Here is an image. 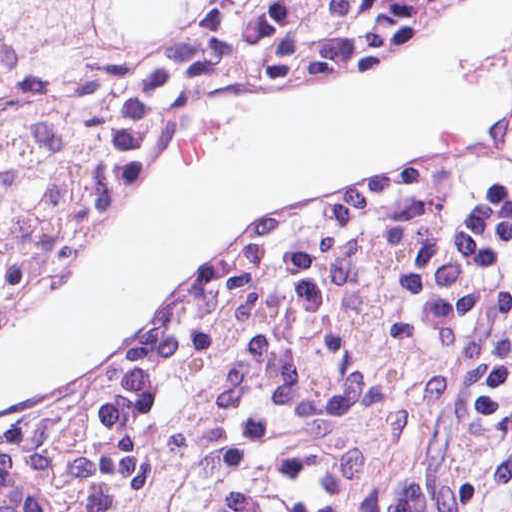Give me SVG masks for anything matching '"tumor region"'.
<instances>
[{"mask_svg": "<svg viewBox=\"0 0 512 512\" xmlns=\"http://www.w3.org/2000/svg\"><path fill=\"white\" fill-rule=\"evenodd\" d=\"M228 1H0V329L86 236L109 147L119 71L150 61ZM0 450L47 512L25 408Z\"/></svg>", "mask_w": 512, "mask_h": 512, "instance_id": "e687c5a6", "label": "tumor region"}]
</instances>
